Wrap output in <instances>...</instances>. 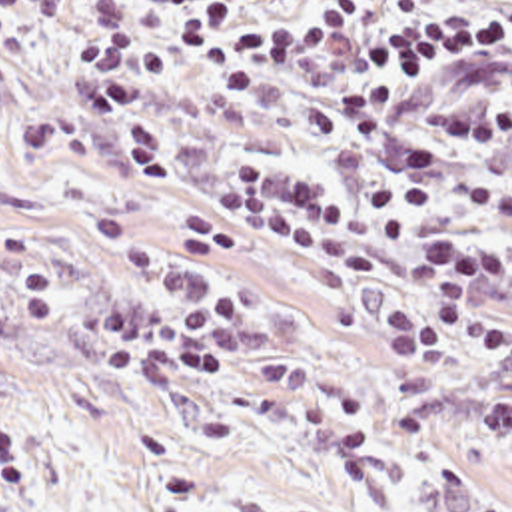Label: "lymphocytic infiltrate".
<instances>
[{
	"instance_id": "lymphocytic-infiltrate-1",
	"label": "lymphocytic infiltrate",
	"mask_w": 512,
	"mask_h": 512,
	"mask_svg": "<svg viewBox=\"0 0 512 512\" xmlns=\"http://www.w3.org/2000/svg\"><path fill=\"white\" fill-rule=\"evenodd\" d=\"M81 88L125 144L141 186L167 176V148L147 98L167 78V50L129 24L123 0H83ZM153 20L205 78L231 98L287 100L319 144L361 162L386 156L400 102L428 76L460 64L512 74V0H143ZM41 0H0V42ZM436 126L480 150L512 138V106H446ZM454 154L436 140L408 142L396 170L353 202L263 154H239L213 184L211 200L241 230L265 236L333 276L374 272L361 228L406 250L410 296L380 322L390 355L414 369H442L470 349L512 365V318L488 302L512 290V190L480 180L466 204L498 218L494 234L470 216H446ZM87 236L117 282L79 310L83 359L135 383H197L225 369L265 324L257 270L241 240L207 212L175 208L155 242L127 210L99 202ZM17 264L31 326L67 318V286L47 232L0 214V284ZM476 427L494 449H512V377L476 405ZM29 459L0 421V507L19 499Z\"/></svg>"
}]
</instances>
